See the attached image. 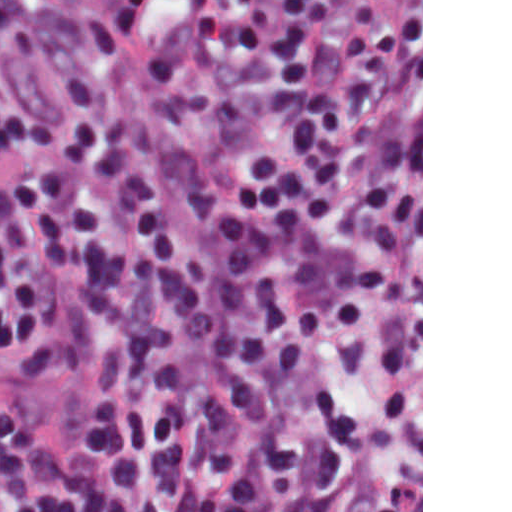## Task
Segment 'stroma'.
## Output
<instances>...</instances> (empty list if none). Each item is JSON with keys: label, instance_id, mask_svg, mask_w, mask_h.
I'll return each mask as SVG.
<instances>
[{"label": "stroma", "instance_id": "35a3bbf8", "mask_svg": "<svg viewBox=\"0 0 512 512\" xmlns=\"http://www.w3.org/2000/svg\"><path fill=\"white\" fill-rule=\"evenodd\" d=\"M374 30L388 75V226L382 287V450L368 512H423V0H329ZM0 34V101L49 116L66 143L84 123L128 125L164 186L205 180L170 87L139 52L108 101L67 108L66 77L91 35L93 0H14ZM0 498L11 505L0 487Z\"/></svg>", "mask_w": 512, "mask_h": 512}]
</instances>
